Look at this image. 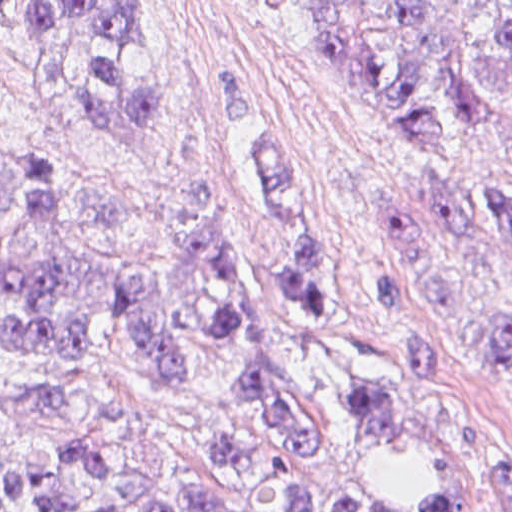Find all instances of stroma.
I'll list each match as a JSON object with an SVG mask.
<instances>
[{"label":"stroma","instance_id":"stroma-1","mask_svg":"<svg viewBox=\"0 0 512 512\" xmlns=\"http://www.w3.org/2000/svg\"><path fill=\"white\" fill-rule=\"evenodd\" d=\"M138 2L145 42L131 50L129 72L153 84L166 121L148 135L95 128L71 88L34 61L0 15V157L17 146L35 151L87 237L128 258L175 247L155 204L202 205L219 193L240 231L276 361L316 431L315 451L293 457L294 474L315 493L319 512L337 503L405 512L429 491L431 463L406 442L353 425L330 345L277 279L290 232L256 177L252 146L286 147L300 170L312 252L331 278L365 376L456 469L466 512H501L491 475L512 470V371L417 286L393 241L390 201L396 183L414 177L483 215L512 187V122L467 151L421 148L431 158L400 140L354 76L317 51L299 13L256 0ZM371 259L397 275L404 321L438 351L435 373L403 366ZM503 268L512 290V249ZM36 370L22 354L0 350L1 458L77 444L128 476L171 488L222 482L206 450L242 421L215 356H200L187 386L164 387L125 326L97 324L74 369L79 405L52 415L18 406Z\"/></svg>","mask_w":512,"mask_h":512}]
</instances>
